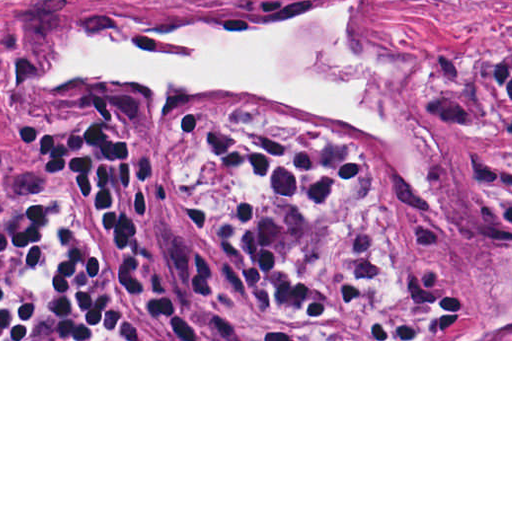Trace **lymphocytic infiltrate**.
<instances>
[{"mask_svg": "<svg viewBox=\"0 0 512 512\" xmlns=\"http://www.w3.org/2000/svg\"><path fill=\"white\" fill-rule=\"evenodd\" d=\"M4 49L0 47V69ZM173 130L209 164L266 181L261 197H222L185 211L191 229L222 248L275 304L273 331L208 315V268L193 261L182 301L161 297L138 261L147 220L139 171L153 150L109 119L48 121L22 152L54 170L48 189L80 196L123 244L185 339H308L307 324L356 314L373 289L362 236L347 241L344 265L329 276L301 271L296 240L347 184L367 174L343 143L323 134L239 130L183 115ZM46 191V190H45ZM45 191L0 221L1 339H170L135 313L108 282L74 261L55 233ZM410 302L386 313L375 339H405Z\"/></svg>", "mask_w": 512, "mask_h": 512, "instance_id": "lymphocytic-infiltrate-1", "label": "lymphocytic infiltrate"}]
</instances>
